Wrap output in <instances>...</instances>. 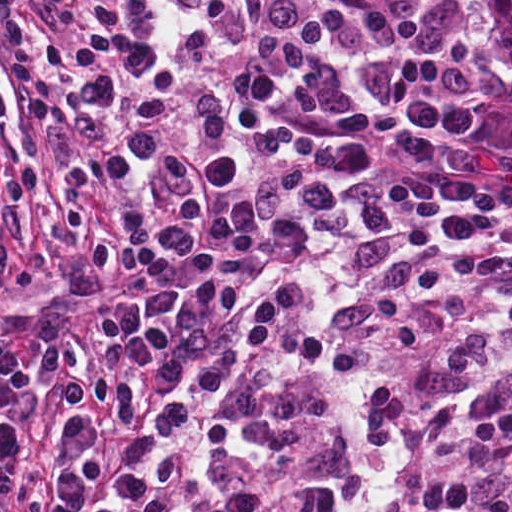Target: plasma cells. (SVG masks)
<instances>
[{"label":"plasma cells","instance_id":"plasma-cells-1","mask_svg":"<svg viewBox=\"0 0 512 512\" xmlns=\"http://www.w3.org/2000/svg\"><path fill=\"white\" fill-rule=\"evenodd\" d=\"M40 91L10 133L0 276L35 287L21 192L54 179L125 294L33 352L0 321V512H159L244 369L225 280L338 200L263 294L257 370L163 512H512V109L433 0H0Z\"/></svg>","mask_w":512,"mask_h":512}]
</instances>
